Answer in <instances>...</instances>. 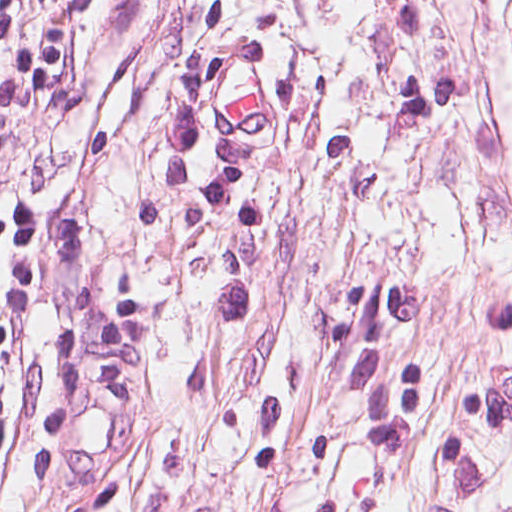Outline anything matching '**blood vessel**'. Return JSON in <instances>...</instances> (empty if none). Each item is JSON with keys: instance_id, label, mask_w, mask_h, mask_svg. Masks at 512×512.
<instances>
[{"instance_id": "obj_1", "label": "blood vessel", "mask_w": 512, "mask_h": 512, "mask_svg": "<svg viewBox=\"0 0 512 512\" xmlns=\"http://www.w3.org/2000/svg\"><path fill=\"white\" fill-rule=\"evenodd\" d=\"M253 53L227 55L209 83L212 112L229 132H276L280 126V101Z\"/></svg>"}]
</instances>
